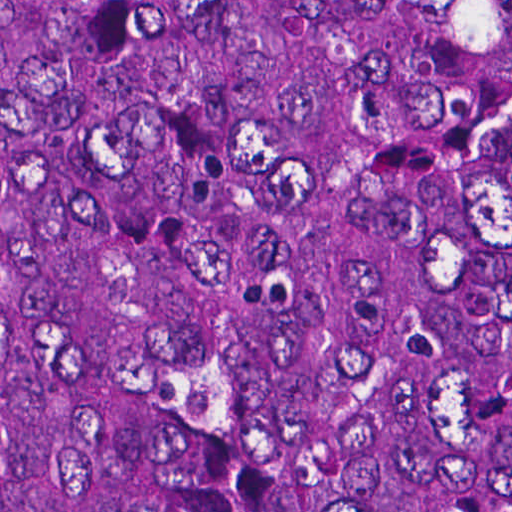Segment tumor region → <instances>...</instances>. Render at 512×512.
Masks as SVG:
<instances>
[{
    "label": "tumor region",
    "instance_id": "e687c5a6",
    "mask_svg": "<svg viewBox=\"0 0 512 512\" xmlns=\"http://www.w3.org/2000/svg\"><path fill=\"white\" fill-rule=\"evenodd\" d=\"M0 512H512V0H0Z\"/></svg>",
    "mask_w": 512,
    "mask_h": 512
}]
</instances>
